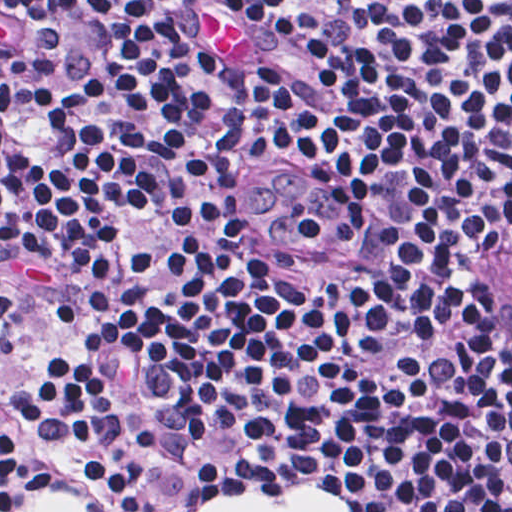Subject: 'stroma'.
<instances>
[{"mask_svg":"<svg viewBox=\"0 0 512 512\" xmlns=\"http://www.w3.org/2000/svg\"><path fill=\"white\" fill-rule=\"evenodd\" d=\"M512 244V213H492L470 227L464 250V276L472 309L494 344L512 383V365L497 331L496 321L484 303L486 280ZM62 321L41 309L10 273L0 271V376L7 362L30 346L50 343ZM57 471L86 463H107L134 475L156 512H197L202 502L221 493L243 497H276L294 487H315L346 502L350 512H360L356 499L338 493L319 481L296 474H164L144 479L110 448L88 452L39 449L22 437ZM49 495L72 496L91 512H111L108 493L96 486H79Z\"/></svg>","mask_w":512,"mask_h":512,"instance_id":"stroma-1","label":"stroma"}]
</instances>
